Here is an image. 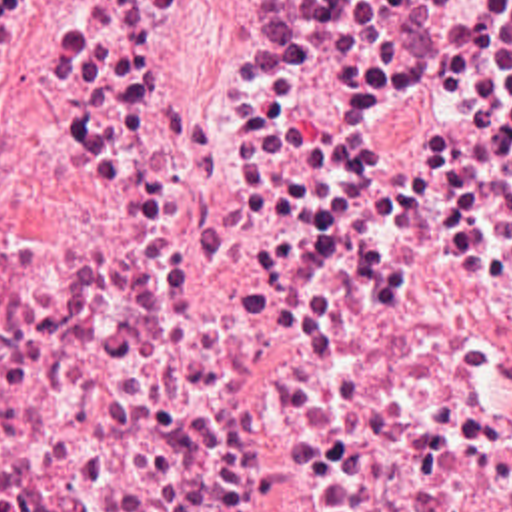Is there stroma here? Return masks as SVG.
<instances>
[{"label": "stroma", "instance_id": "1", "mask_svg": "<svg viewBox=\"0 0 512 512\" xmlns=\"http://www.w3.org/2000/svg\"><path fill=\"white\" fill-rule=\"evenodd\" d=\"M247 0H159L133 97L223 117V51Z\"/></svg>", "mask_w": 512, "mask_h": 512}]
</instances>
